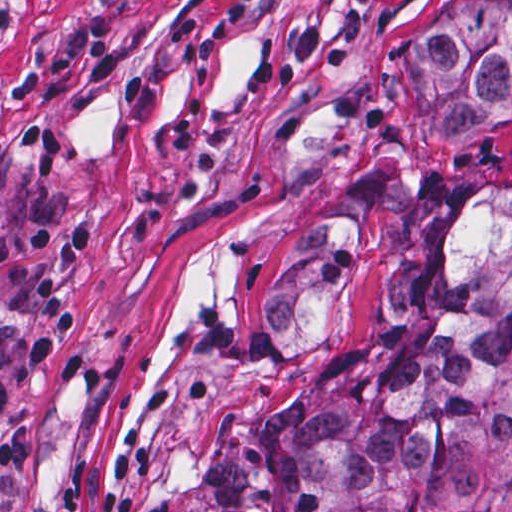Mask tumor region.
I'll return each instance as SVG.
<instances>
[{"mask_svg":"<svg viewBox=\"0 0 512 512\" xmlns=\"http://www.w3.org/2000/svg\"><path fill=\"white\" fill-rule=\"evenodd\" d=\"M412 88L445 132L492 128L512 101V0H467L412 52ZM372 222L335 195L280 246L259 358L312 373L213 430L193 512H512V169L408 196L383 311L333 356Z\"/></svg>","mask_w":512,"mask_h":512,"instance_id":"e687c5a6","label":"tumor region"}]
</instances>
